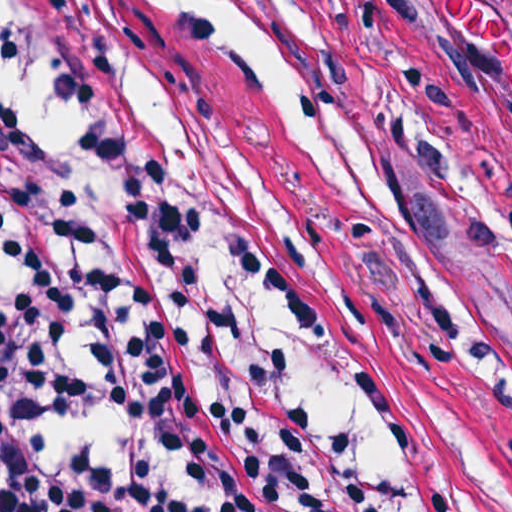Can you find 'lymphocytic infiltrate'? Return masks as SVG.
Returning a JSON list of instances; mask_svg holds the SVG:
<instances>
[{"label":"lymphocytic infiltrate","instance_id":"f902f5d3","mask_svg":"<svg viewBox=\"0 0 512 512\" xmlns=\"http://www.w3.org/2000/svg\"><path fill=\"white\" fill-rule=\"evenodd\" d=\"M71 132L0 105V512H311L200 375L47 0H2Z\"/></svg>","mask_w":512,"mask_h":512}]
</instances>
